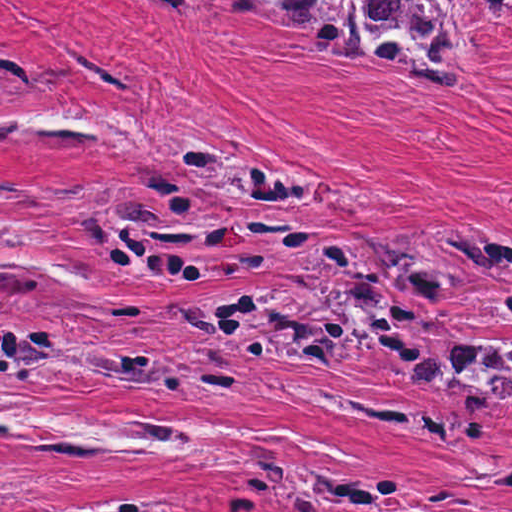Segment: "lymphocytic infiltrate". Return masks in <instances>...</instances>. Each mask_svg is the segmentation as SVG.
Instances as JSON below:
<instances>
[{"label":"lymphocytic infiltrate","mask_w":512,"mask_h":512,"mask_svg":"<svg viewBox=\"0 0 512 512\" xmlns=\"http://www.w3.org/2000/svg\"><path fill=\"white\" fill-rule=\"evenodd\" d=\"M23 354V330L1 310V369L6 362L15 361Z\"/></svg>","instance_id":"lymphocytic-infiltrate-1"}]
</instances>
